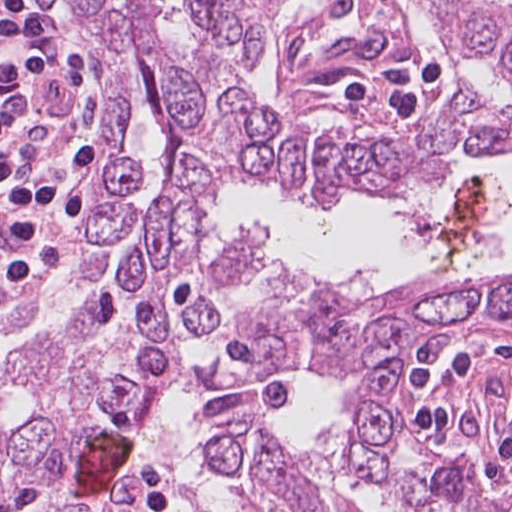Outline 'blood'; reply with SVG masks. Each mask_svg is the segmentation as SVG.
Segmentation results:
<instances>
[{
    "label": "blood",
    "instance_id": "obj_1",
    "mask_svg": "<svg viewBox=\"0 0 512 512\" xmlns=\"http://www.w3.org/2000/svg\"><path fill=\"white\" fill-rule=\"evenodd\" d=\"M129 454L128 434L103 432L87 439L78 452V465L85 484V495L95 490L105 473L127 460Z\"/></svg>",
    "mask_w": 512,
    "mask_h": 512
}]
</instances>
